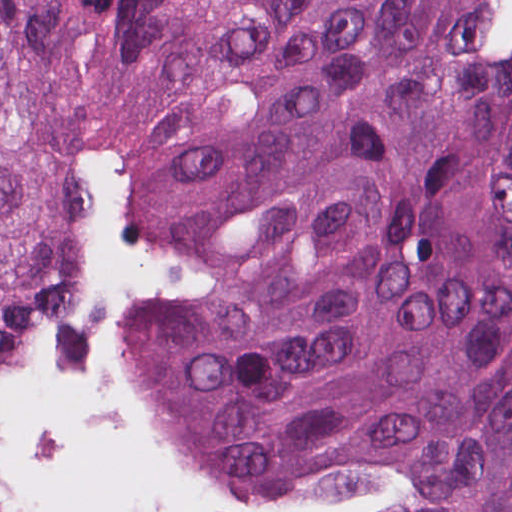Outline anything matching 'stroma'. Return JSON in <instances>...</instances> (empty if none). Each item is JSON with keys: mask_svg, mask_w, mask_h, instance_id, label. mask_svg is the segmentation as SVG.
<instances>
[{"mask_svg": "<svg viewBox=\"0 0 512 512\" xmlns=\"http://www.w3.org/2000/svg\"><path fill=\"white\" fill-rule=\"evenodd\" d=\"M135 0H110V66L130 52ZM100 177L122 188L146 241L172 254L182 278L156 273L118 295L109 317V348L118 398L138 445L174 485L214 512H339L372 504L396 481L357 459L307 466L261 495L226 494L196 464L154 400L144 373V334L168 310H210L216 294L213 270L178 243L158 235L151 220L156 179L142 167L113 164L100 151ZM98 244L95 206L91 227V275ZM84 295L56 329L6 351L0 386L26 369L81 311ZM0 512H18L12 456L0 451Z\"/></svg>", "mask_w": 512, "mask_h": 512, "instance_id": "35a3bbf8", "label": "stroma"}]
</instances>
